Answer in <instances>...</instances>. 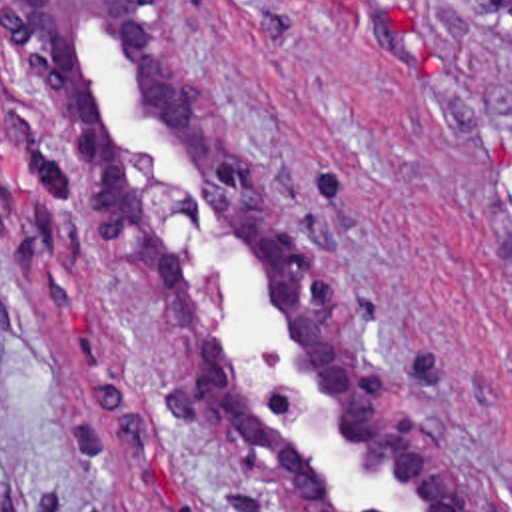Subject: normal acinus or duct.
<instances>
[{
	"instance_id": "normal-acinus-or-duct-1",
	"label": "normal acinus or duct",
	"mask_w": 512,
	"mask_h": 512,
	"mask_svg": "<svg viewBox=\"0 0 512 512\" xmlns=\"http://www.w3.org/2000/svg\"><path fill=\"white\" fill-rule=\"evenodd\" d=\"M0 63L118 305L172 358L170 404L254 462L284 512H479L224 115L180 0H0Z\"/></svg>"
}]
</instances>
